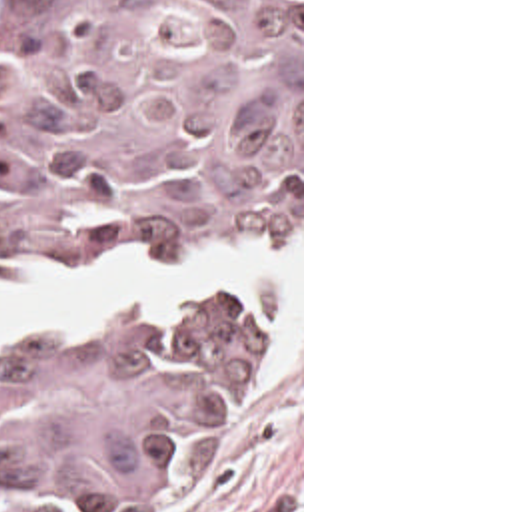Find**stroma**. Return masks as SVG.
Listing matches in <instances>:
<instances>
[{"instance_id": "1", "label": "stroma", "mask_w": 512, "mask_h": 512, "mask_svg": "<svg viewBox=\"0 0 512 512\" xmlns=\"http://www.w3.org/2000/svg\"><path fill=\"white\" fill-rule=\"evenodd\" d=\"M0 0V23L4 13ZM280 231L300 233L298 341L288 361L262 385L250 379L266 361L276 323L268 299V323L234 375L232 395L216 419L206 456L194 480L146 510L122 512H304V0H300V209L246 239H146L130 245H90L52 253L26 269H0V281H14L40 267L88 265L110 255H136L168 263L216 243L254 241ZM216 291H256L224 287ZM188 303V301H186ZM184 305V303H182ZM180 305H140L100 321L88 331H32L0 339V345H104L146 335Z\"/></svg>"}]
</instances>
